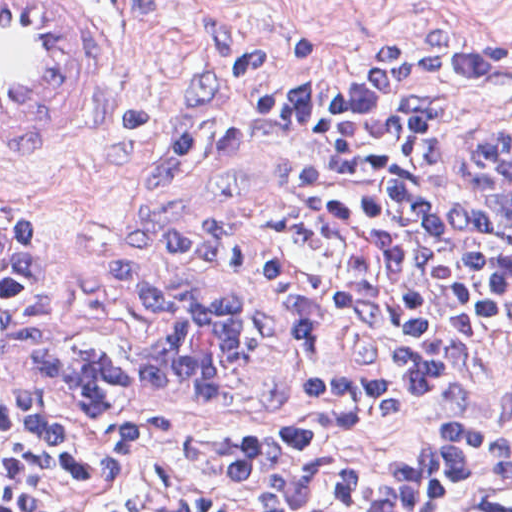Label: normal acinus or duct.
<instances>
[{
	"instance_id": "normal-acinus-or-duct-1",
	"label": "normal acinus or duct",
	"mask_w": 512,
	"mask_h": 512,
	"mask_svg": "<svg viewBox=\"0 0 512 512\" xmlns=\"http://www.w3.org/2000/svg\"><path fill=\"white\" fill-rule=\"evenodd\" d=\"M463 136L458 187L512 210V127L471 123ZM202 280L161 287L100 319L68 325L44 343L42 364L69 387L165 406L237 402L261 377L266 327ZM453 512H512V482L494 484L480 506Z\"/></svg>"
}]
</instances>
